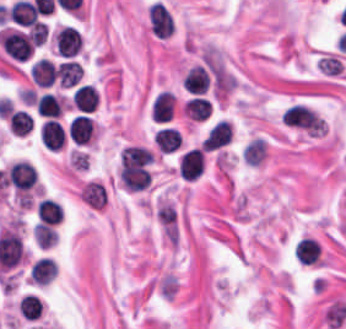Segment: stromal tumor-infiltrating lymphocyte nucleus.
Here are the masks:
<instances>
[{"label": "stromal tumor-infiltrating lymphocyte nucleus", "instance_id": "bc302bb0", "mask_svg": "<svg viewBox=\"0 0 346 329\" xmlns=\"http://www.w3.org/2000/svg\"><path fill=\"white\" fill-rule=\"evenodd\" d=\"M150 30L155 36L167 37L172 33L174 21L169 9L159 0L149 5Z\"/></svg>", "mask_w": 346, "mask_h": 329}, {"label": "stromal tumor-infiltrating lymphocyte nucleus", "instance_id": "52c7bb5b", "mask_svg": "<svg viewBox=\"0 0 346 329\" xmlns=\"http://www.w3.org/2000/svg\"><path fill=\"white\" fill-rule=\"evenodd\" d=\"M83 42L75 27L63 26L55 33L56 52L60 57H75Z\"/></svg>", "mask_w": 346, "mask_h": 329}, {"label": "stromal tumor-infiltrating lymphocyte nucleus", "instance_id": "3290ff9b", "mask_svg": "<svg viewBox=\"0 0 346 329\" xmlns=\"http://www.w3.org/2000/svg\"><path fill=\"white\" fill-rule=\"evenodd\" d=\"M68 132L78 145L89 143L94 133L93 118L84 113H77L68 123Z\"/></svg>", "mask_w": 346, "mask_h": 329}, {"label": "stromal tumor-infiltrating lymphocyte nucleus", "instance_id": "abfb95fc", "mask_svg": "<svg viewBox=\"0 0 346 329\" xmlns=\"http://www.w3.org/2000/svg\"><path fill=\"white\" fill-rule=\"evenodd\" d=\"M179 167L182 178L194 179L202 174L204 167L203 151L191 148L184 151L179 158Z\"/></svg>", "mask_w": 346, "mask_h": 329}, {"label": "stromal tumor-infiltrating lymphocyte nucleus", "instance_id": "9ea309e8", "mask_svg": "<svg viewBox=\"0 0 346 329\" xmlns=\"http://www.w3.org/2000/svg\"><path fill=\"white\" fill-rule=\"evenodd\" d=\"M231 139V127L229 121L226 119H219L215 124H213L203 142L202 149L211 150L222 145L228 144Z\"/></svg>", "mask_w": 346, "mask_h": 329}, {"label": "stromal tumor-infiltrating lymphocyte nucleus", "instance_id": "f3e2335f", "mask_svg": "<svg viewBox=\"0 0 346 329\" xmlns=\"http://www.w3.org/2000/svg\"><path fill=\"white\" fill-rule=\"evenodd\" d=\"M176 96L170 89H163L152 103V115L159 122L174 117Z\"/></svg>", "mask_w": 346, "mask_h": 329}, {"label": "stromal tumor-infiltrating lymphocyte nucleus", "instance_id": "4f13568d", "mask_svg": "<svg viewBox=\"0 0 346 329\" xmlns=\"http://www.w3.org/2000/svg\"><path fill=\"white\" fill-rule=\"evenodd\" d=\"M58 273V263L50 256H42L30 269V281L35 284H48Z\"/></svg>", "mask_w": 346, "mask_h": 329}, {"label": "stromal tumor-infiltrating lymphocyte nucleus", "instance_id": "2a367800", "mask_svg": "<svg viewBox=\"0 0 346 329\" xmlns=\"http://www.w3.org/2000/svg\"><path fill=\"white\" fill-rule=\"evenodd\" d=\"M42 144L50 149H59L66 141V133L56 118H49L42 126L40 131Z\"/></svg>", "mask_w": 346, "mask_h": 329}, {"label": "stromal tumor-infiltrating lymphocyte nucleus", "instance_id": "4803ca6d", "mask_svg": "<svg viewBox=\"0 0 346 329\" xmlns=\"http://www.w3.org/2000/svg\"><path fill=\"white\" fill-rule=\"evenodd\" d=\"M210 77L207 68L192 65L182 78V87L195 93H204L209 85Z\"/></svg>", "mask_w": 346, "mask_h": 329}, {"label": "stromal tumor-infiltrating lymphocyte nucleus", "instance_id": "4245b91a", "mask_svg": "<svg viewBox=\"0 0 346 329\" xmlns=\"http://www.w3.org/2000/svg\"><path fill=\"white\" fill-rule=\"evenodd\" d=\"M56 75V67L47 59L39 58L30 67L31 80L40 86H48Z\"/></svg>", "mask_w": 346, "mask_h": 329}, {"label": "stromal tumor-infiltrating lymphocyte nucleus", "instance_id": "4c9ddf68", "mask_svg": "<svg viewBox=\"0 0 346 329\" xmlns=\"http://www.w3.org/2000/svg\"><path fill=\"white\" fill-rule=\"evenodd\" d=\"M98 97L95 86L82 83L76 86L72 100L77 108L90 112L96 108Z\"/></svg>", "mask_w": 346, "mask_h": 329}, {"label": "stromal tumor-infiltrating lymphocyte nucleus", "instance_id": "2761f720", "mask_svg": "<svg viewBox=\"0 0 346 329\" xmlns=\"http://www.w3.org/2000/svg\"><path fill=\"white\" fill-rule=\"evenodd\" d=\"M320 252L318 242L310 236H303L294 247V254L304 264H314Z\"/></svg>", "mask_w": 346, "mask_h": 329}, {"label": "stromal tumor-infiltrating lymphocyte nucleus", "instance_id": "3c572f05", "mask_svg": "<svg viewBox=\"0 0 346 329\" xmlns=\"http://www.w3.org/2000/svg\"><path fill=\"white\" fill-rule=\"evenodd\" d=\"M39 221L42 224H55L62 219L61 204L50 198L40 199L37 207Z\"/></svg>", "mask_w": 346, "mask_h": 329}, {"label": "stromal tumor-infiltrating lymphocyte nucleus", "instance_id": "42bb06b2", "mask_svg": "<svg viewBox=\"0 0 346 329\" xmlns=\"http://www.w3.org/2000/svg\"><path fill=\"white\" fill-rule=\"evenodd\" d=\"M212 103L206 96L192 95L183 106L182 111L192 119H206Z\"/></svg>", "mask_w": 346, "mask_h": 329}, {"label": "stromal tumor-infiltrating lymphocyte nucleus", "instance_id": "9e4306bb", "mask_svg": "<svg viewBox=\"0 0 346 329\" xmlns=\"http://www.w3.org/2000/svg\"><path fill=\"white\" fill-rule=\"evenodd\" d=\"M56 71L65 87L77 85L83 74L77 60H63Z\"/></svg>", "mask_w": 346, "mask_h": 329}, {"label": "stromal tumor-infiltrating lymphocyte nucleus", "instance_id": "04cf8593", "mask_svg": "<svg viewBox=\"0 0 346 329\" xmlns=\"http://www.w3.org/2000/svg\"><path fill=\"white\" fill-rule=\"evenodd\" d=\"M180 139L181 137L176 127L171 126H164L154 134V141L163 152H171L177 148Z\"/></svg>", "mask_w": 346, "mask_h": 329}, {"label": "stromal tumor-infiltrating lymphocyte nucleus", "instance_id": "e9af9c67", "mask_svg": "<svg viewBox=\"0 0 346 329\" xmlns=\"http://www.w3.org/2000/svg\"><path fill=\"white\" fill-rule=\"evenodd\" d=\"M36 112L47 117H57L62 113V105L55 94L51 91H44L38 96Z\"/></svg>", "mask_w": 346, "mask_h": 329}, {"label": "stromal tumor-infiltrating lymphocyte nucleus", "instance_id": "782c7336", "mask_svg": "<svg viewBox=\"0 0 346 329\" xmlns=\"http://www.w3.org/2000/svg\"><path fill=\"white\" fill-rule=\"evenodd\" d=\"M43 302L34 293H26L18 300V311L28 319H35L42 314Z\"/></svg>", "mask_w": 346, "mask_h": 329}, {"label": "stromal tumor-infiltrating lymphocyte nucleus", "instance_id": "cac63f63", "mask_svg": "<svg viewBox=\"0 0 346 329\" xmlns=\"http://www.w3.org/2000/svg\"><path fill=\"white\" fill-rule=\"evenodd\" d=\"M267 144L261 138H254L245 146V161L249 165H260L266 157Z\"/></svg>", "mask_w": 346, "mask_h": 329}, {"label": "stromal tumor-infiltrating lymphocyte nucleus", "instance_id": "2e467ee5", "mask_svg": "<svg viewBox=\"0 0 346 329\" xmlns=\"http://www.w3.org/2000/svg\"><path fill=\"white\" fill-rule=\"evenodd\" d=\"M57 231L53 226L38 222L34 225V239L41 248H48L56 243Z\"/></svg>", "mask_w": 346, "mask_h": 329}]
</instances>
